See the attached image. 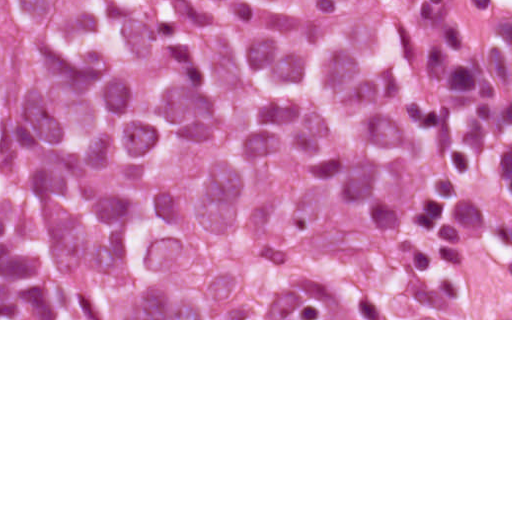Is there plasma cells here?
I'll return each mask as SVG.
<instances>
[{
    "mask_svg": "<svg viewBox=\"0 0 512 512\" xmlns=\"http://www.w3.org/2000/svg\"><path fill=\"white\" fill-rule=\"evenodd\" d=\"M455 2L512 38V0H455Z\"/></svg>",
    "mask_w": 512,
    "mask_h": 512,
    "instance_id": "obj_1",
    "label": "plasma cells"
}]
</instances>
